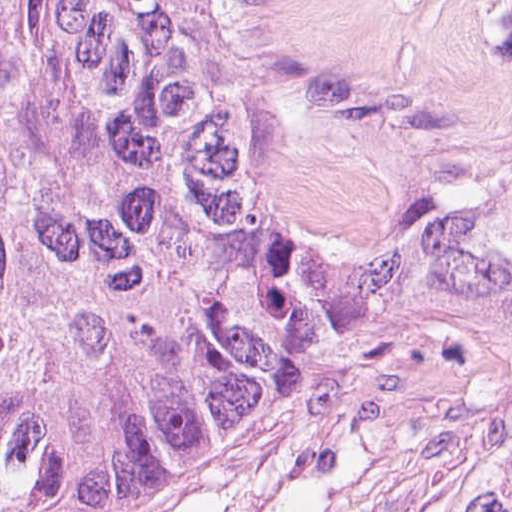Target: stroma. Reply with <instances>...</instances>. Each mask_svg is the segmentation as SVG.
<instances>
[{
	"label": "stroma",
	"mask_w": 512,
	"mask_h": 512,
	"mask_svg": "<svg viewBox=\"0 0 512 512\" xmlns=\"http://www.w3.org/2000/svg\"><path fill=\"white\" fill-rule=\"evenodd\" d=\"M275 215L313 279L512 174V0H283ZM322 314L285 434L195 499L107 512H444L499 407L416 317Z\"/></svg>",
	"instance_id": "obj_1"
}]
</instances>
